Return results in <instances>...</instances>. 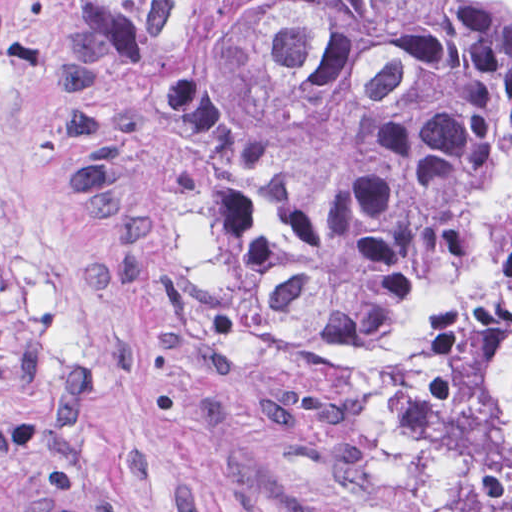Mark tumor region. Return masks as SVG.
Segmentation results:
<instances>
[{
	"label": "tumor region",
	"mask_w": 512,
	"mask_h": 512,
	"mask_svg": "<svg viewBox=\"0 0 512 512\" xmlns=\"http://www.w3.org/2000/svg\"><path fill=\"white\" fill-rule=\"evenodd\" d=\"M49 147L158 364L423 512H512V0H60Z\"/></svg>",
	"instance_id": "obj_1"
}]
</instances>
